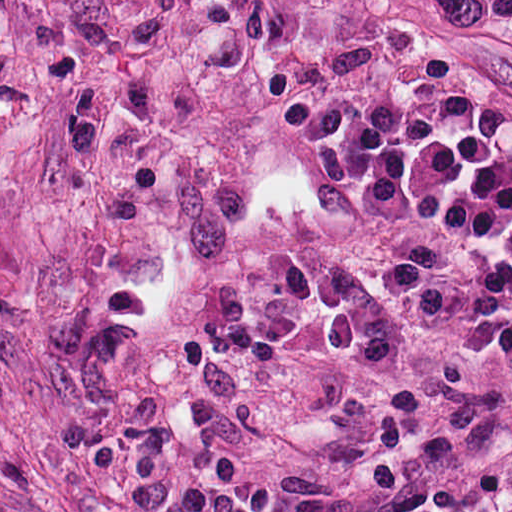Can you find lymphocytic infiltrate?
I'll list each match as a JSON object with an SVG mask.
<instances>
[{"label":"lymphocytic infiltrate","instance_id":"obj_1","mask_svg":"<svg viewBox=\"0 0 512 512\" xmlns=\"http://www.w3.org/2000/svg\"><path fill=\"white\" fill-rule=\"evenodd\" d=\"M363 270L409 324L496 362L512 412V257L489 252L461 263L394 240Z\"/></svg>","mask_w":512,"mask_h":512}]
</instances>
